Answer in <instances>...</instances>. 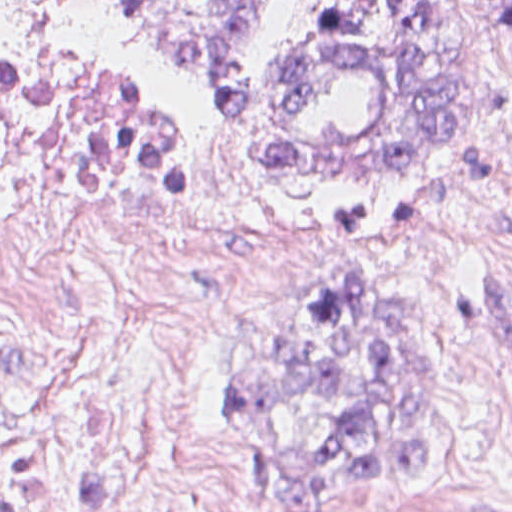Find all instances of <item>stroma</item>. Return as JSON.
Instances as JSON below:
<instances>
[{
    "label": "stroma",
    "mask_w": 512,
    "mask_h": 512,
    "mask_svg": "<svg viewBox=\"0 0 512 512\" xmlns=\"http://www.w3.org/2000/svg\"><path fill=\"white\" fill-rule=\"evenodd\" d=\"M479 1L468 6L477 96L443 158L271 183L217 95L147 38L132 0H0V61L37 45L124 50L155 113L199 146L244 232L285 260L279 286L202 331L189 354L218 492L238 512L297 511L240 449L231 375L279 347L306 284L343 272L390 284L436 343L433 461L412 486L365 484L318 512L512 510V37Z\"/></svg>",
    "instance_id": "obj_1"
}]
</instances>
